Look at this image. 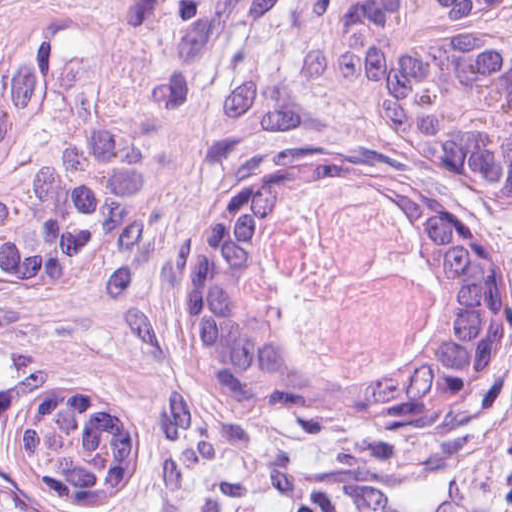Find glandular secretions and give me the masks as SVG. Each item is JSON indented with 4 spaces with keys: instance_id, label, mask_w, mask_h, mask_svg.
Returning a JSON list of instances; mask_svg holds the SVG:
<instances>
[{
    "instance_id": "b5bd25d6",
    "label": "glandular secretions",
    "mask_w": 512,
    "mask_h": 512,
    "mask_svg": "<svg viewBox=\"0 0 512 512\" xmlns=\"http://www.w3.org/2000/svg\"><path fill=\"white\" fill-rule=\"evenodd\" d=\"M370 189L301 197L251 248L246 300L263 341L300 378L396 393L453 351L423 228L359 204Z\"/></svg>"
}]
</instances>
